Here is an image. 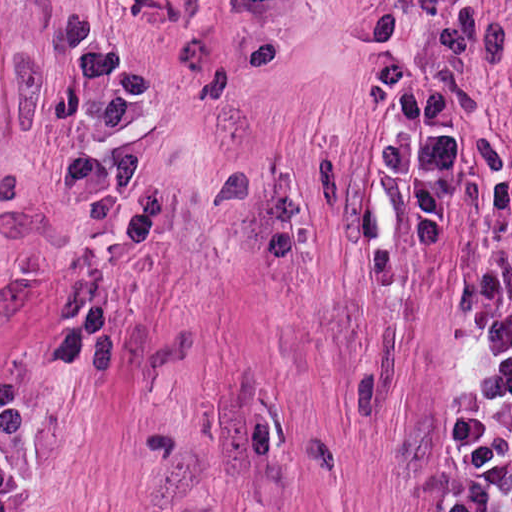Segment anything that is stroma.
Returning a JSON list of instances; mask_svg holds the SVG:
<instances>
[{
  "label": "stroma",
  "instance_id": "obj_1",
  "mask_svg": "<svg viewBox=\"0 0 512 512\" xmlns=\"http://www.w3.org/2000/svg\"><path fill=\"white\" fill-rule=\"evenodd\" d=\"M374 1L204 0L38 512H424L470 252L512 264V0H463L497 45L434 248L377 168Z\"/></svg>",
  "mask_w": 512,
  "mask_h": 512
}]
</instances>
